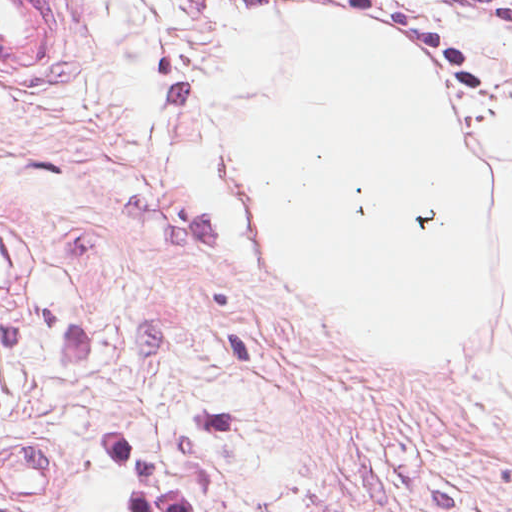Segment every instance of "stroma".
<instances>
[{"label": "stroma", "instance_id": "35a3bbf8", "mask_svg": "<svg viewBox=\"0 0 512 512\" xmlns=\"http://www.w3.org/2000/svg\"><path fill=\"white\" fill-rule=\"evenodd\" d=\"M512 53V0H268Z\"/></svg>", "mask_w": 512, "mask_h": 512}]
</instances>
